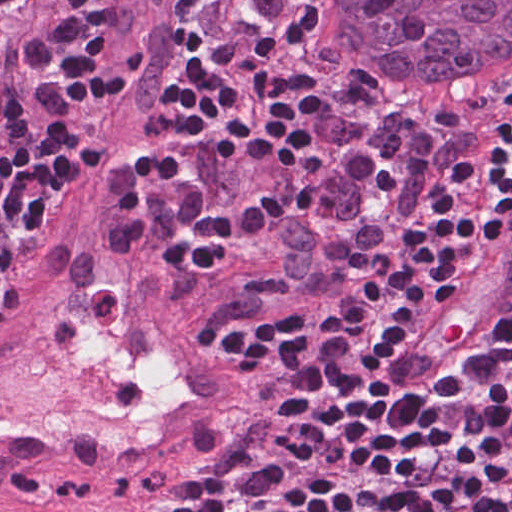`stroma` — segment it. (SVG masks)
<instances>
[{"label":"stroma","mask_w":512,"mask_h":512,"mask_svg":"<svg viewBox=\"0 0 512 512\" xmlns=\"http://www.w3.org/2000/svg\"><path fill=\"white\" fill-rule=\"evenodd\" d=\"M126 4L106 0L90 21L99 60L119 74L116 84L128 56ZM193 62L194 0H182L162 116L134 149L115 147L97 130L78 176L126 161L147 171L157 149L192 164L210 200H233L252 178L241 171L219 128L196 121L176 95ZM429 105L457 117L505 112L512 109V75L468 86H384L311 42L293 82L290 121L291 145L306 181L302 201L240 268L203 289L216 327L272 333L320 311L335 317L404 271L411 223L395 186V129L324 140ZM144 200L170 252L173 221L149 173ZM219 344L246 386L250 418L198 448L108 477L0 491V512H169L184 493L258 447L266 436V386L244 347Z\"/></svg>","instance_id":"35a3bbf8"}]
</instances>
